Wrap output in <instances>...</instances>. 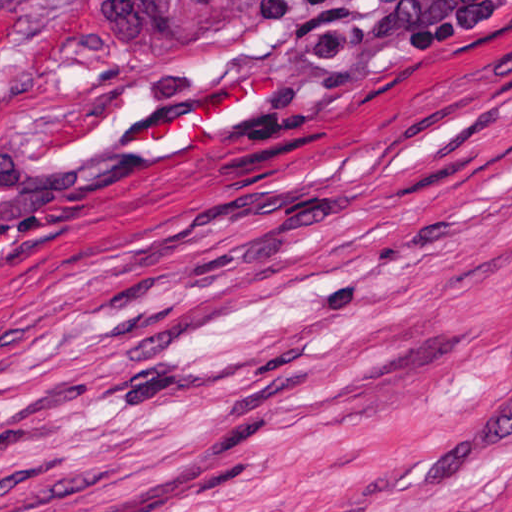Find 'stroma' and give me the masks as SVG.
<instances>
[{"instance_id":"1","label":"stroma","mask_w":512,"mask_h":512,"mask_svg":"<svg viewBox=\"0 0 512 512\" xmlns=\"http://www.w3.org/2000/svg\"><path fill=\"white\" fill-rule=\"evenodd\" d=\"M0 512H512V0L75 74L0 1Z\"/></svg>"}]
</instances>
